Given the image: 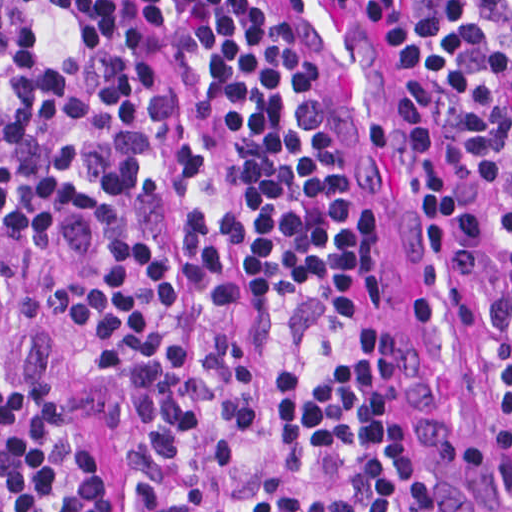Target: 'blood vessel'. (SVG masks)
<instances>
[{
	"label": "blood vessel",
	"instance_id": "blood-vessel-1",
	"mask_svg": "<svg viewBox=\"0 0 512 512\" xmlns=\"http://www.w3.org/2000/svg\"><path fill=\"white\" fill-rule=\"evenodd\" d=\"M307 71L446 512H512V400L434 133L352 0H246Z\"/></svg>",
	"mask_w": 512,
	"mask_h": 512
}]
</instances>
